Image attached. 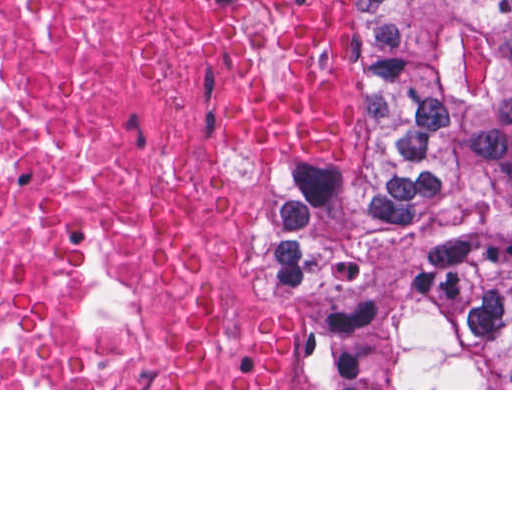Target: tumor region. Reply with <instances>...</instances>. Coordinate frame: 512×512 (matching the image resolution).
Instances as JSON below:
<instances>
[{
    "mask_svg": "<svg viewBox=\"0 0 512 512\" xmlns=\"http://www.w3.org/2000/svg\"><path fill=\"white\" fill-rule=\"evenodd\" d=\"M371 177L253 215L302 306V389H512V0H365Z\"/></svg>",
    "mask_w": 512,
    "mask_h": 512,
    "instance_id": "e687c5a6",
    "label": "tumor region"
}]
</instances>
